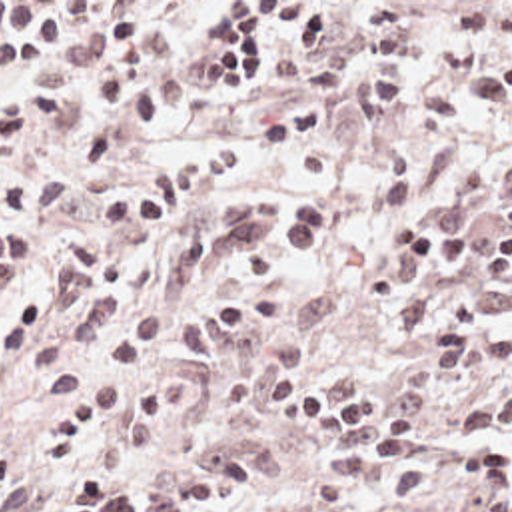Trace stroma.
I'll return each instance as SVG.
<instances>
[{"label": "stroma", "instance_id": "35a3bbf8", "mask_svg": "<svg viewBox=\"0 0 512 512\" xmlns=\"http://www.w3.org/2000/svg\"><path fill=\"white\" fill-rule=\"evenodd\" d=\"M0 2H85V20L71 40L47 56L51 62L75 60L85 44L101 2H188L169 38L171 68L184 90L179 118L153 128L95 176L81 182L53 220L39 268L21 284L0 292L1 308L23 292L47 288L53 258L63 240L81 236L103 242L97 208L101 200L161 162L181 154H204L232 148L238 156L234 180L206 204L226 196H276L310 192L326 212L330 230L308 258L314 278L288 286L282 298L330 288L338 296L334 317L312 337L306 359L344 367L362 375L374 391L386 395L398 377L420 359L422 349L400 335V310L368 304L364 278L394 264L382 228L390 220L432 218L456 234H488L512 218V112L472 120L460 112L462 84L478 68L500 56L496 40L476 56L432 60L414 70V86L404 108L384 120L368 118L362 106V60L370 24L360 2H412L422 40L442 46L452 26V10L462 2L512 0H0ZM222 2H318L324 6V52L320 58H298L296 30L272 16L262 18V44L250 88H208L202 72L214 62L212 48L202 44L204 30ZM344 60V96L334 104L324 140L332 170L328 178H300L294 156H268L256 130L264 116L282 108L300 92L310 72L322 62ZM91 84L67 78L57 90V112L35 126L15 158L0 166V192L13 180L59 164L85 146L91 130ZM472 272L454 248L438 252ZM175 321L163 343L135 369L143 375H175L190 387V403L171 435L151 453L135 459L99 463L111 479L143 495L159 481L202 455L226 445H242L260 463V481L238 503L216 512H512V495L490 501L480 493L442 487L412 507H396L386 485L348 501L326 483V453L306 437L272 419L266 409L236 413L220 395V375L230 357L246 343L216 361L188 359L177 341ZM53 399L31 369L25 351L0 361V447L25 459L39 491L29 512H55L67 495L69 471L77 465H55L41 453V433Z\"/></svg>", "mask_w": 512, "mask_h": 512}]
</instances>
